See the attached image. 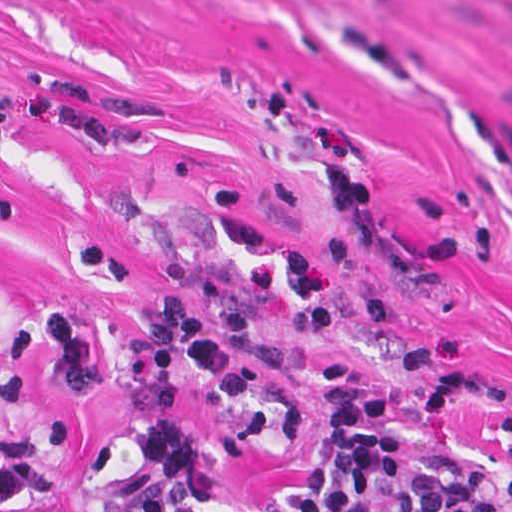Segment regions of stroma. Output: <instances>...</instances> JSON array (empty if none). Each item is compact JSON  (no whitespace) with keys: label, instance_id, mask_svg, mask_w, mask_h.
<instances>
[{"label":"stroma","instance_id":"stroma-1","mask_svg":"<svg viewBox=\"0 0 512 512\" xmlns=\"http://www.w3.org/2000/svg\"><path fill=\"white\" fill-rule=\"evenodd\" d=\"M168 282L251 293L294 345L255 374L281 408H311L326 360L467 382L425 423L256 435L189 380L201 466L163 512L296 489L344 437L512 456V0H0V384L36 312L123 344ZM28 372L26 427L70 414L76 458L0 512H113L121 393L102 366L86 402Z\"/></svg>","mask_w":512,"mask_h":512}]
</instances>
